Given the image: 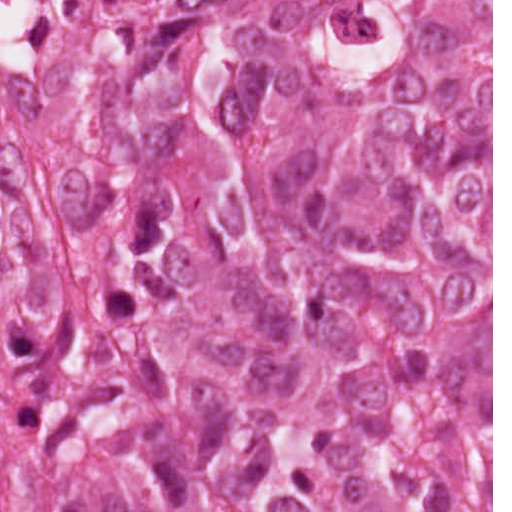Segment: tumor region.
Listing matches in <instances>:
<instances>
[{
  "mask_svg": "<svg viewBox=\"0 0 512 512\" xmlns=\"http://www.w3.org/2000/svg\"><path fill=\"white\" fill-rule=\"evenodd\" d=\"M78 254L0 193V512H492V0H128Z\"/></svg>",
  "mask_w": 512,
  "mask_h": 512,
  "instance_id": "obj_1",
  "label": "tumor region"
}]
</instances>
